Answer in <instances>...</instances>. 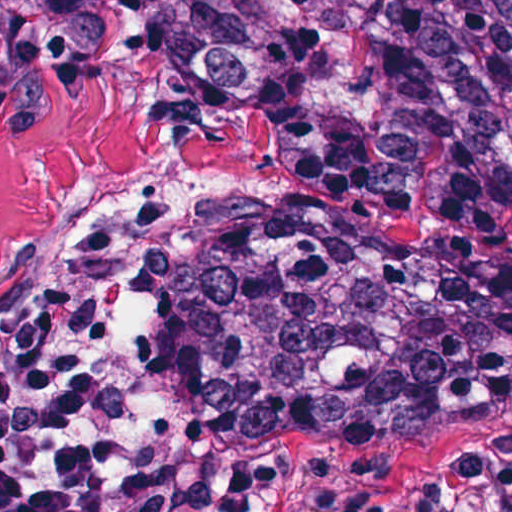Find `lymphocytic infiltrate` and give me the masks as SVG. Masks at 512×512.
I'll return each instance as SVG.
<instances>
[{
	"mask_svg": "<svg viewBox=\"0 0 512 512\" xmlns=\"http://www.w3.org/2000/svg\"><path fill=\"white\" fill-rule=\"evenodd\" d=\"M182 494L121 295L102 268H63L0 324V512H179Z\"/></svg>",
	"mask_w": 512,
	"mask_h": 512,
	"instance_id": "lymphocytic-infiltrate-1",
	"label": "lymphocytic infiltrate"
}]
</instances>
